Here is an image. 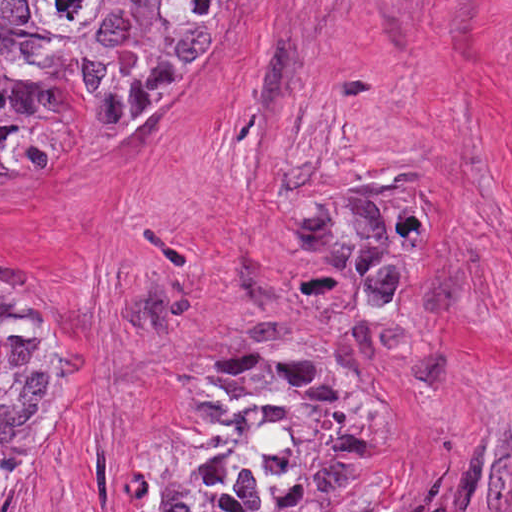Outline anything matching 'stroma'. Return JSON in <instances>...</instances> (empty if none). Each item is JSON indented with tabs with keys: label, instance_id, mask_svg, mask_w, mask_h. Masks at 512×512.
Returning <instances> with one entry per match:
<instances>
[{
	"label": "stroma",
	"instance_id": "1",
	"mask_svg": "<svg viewBox=\"0 0 512 512\" xmlns=\"http://www.w3.org/2000/svg\"><path fill=\"white\" fill-rule=\"evenodd\" d=\"M55 163L0 177V283L61 341L6 512H160L168 416L222 347L332 318L320 230L417 204V261L338 360L374 406L354 512H512V0H224L168 146L90 138L70 74Z\"/></svg>",
	"mask_w": 512,
	"mask_h": 512
}]
</instances>
